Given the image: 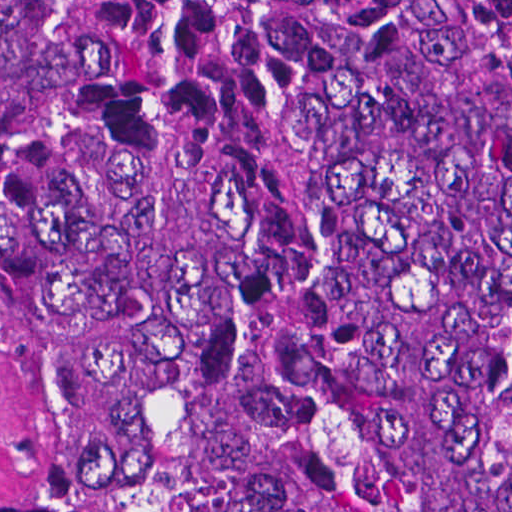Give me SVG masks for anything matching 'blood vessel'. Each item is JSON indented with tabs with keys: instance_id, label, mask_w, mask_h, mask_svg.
Listing matches in <instances>:
<instances>
[{
	"instance_id": "8fb6f2fc",
	"label": "blood vessel",
	"mask_w": 512,
	"mask_h": 512,
	"mask_svg": "<svg viewBox=\"0 0 512 512\" xmlns=\"http://www.w3.org/2000/svg\"><path fill=\"white\" fill-rule=\"evenodd\" d=\"M30 400L26 328L0 301V472L19 454Z\"/></svg>"
}]
</instances>
